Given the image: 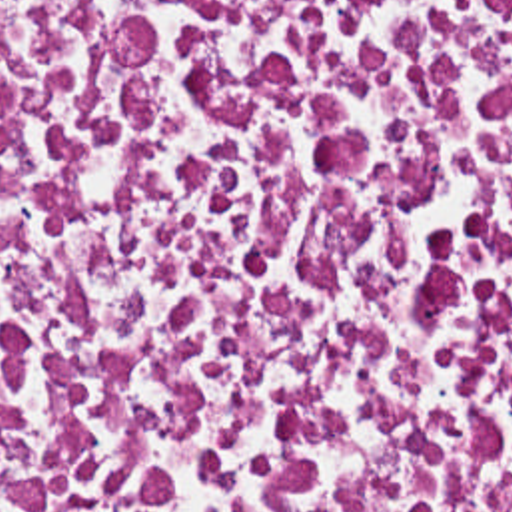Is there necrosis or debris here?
Wrapping results in <instances>:
<instances>
[{
    "instance_id": "obj_1",
    "label": "necrosis or debris",
    "mask_w": 512,
    "mask_h": 512,
    "mask_svg": "<svg viewBox=\"0 0 512 512\" xmlns=\"http://www.w3.org/2000/svg\"><path fill=\"white\" fill-rule=\"evenodd\" d=\"M0 512H512V0H0Z\"/></svg>"
}]
</instances>
